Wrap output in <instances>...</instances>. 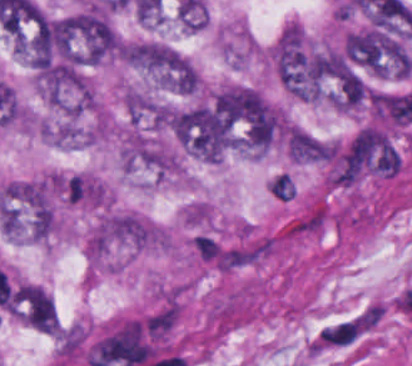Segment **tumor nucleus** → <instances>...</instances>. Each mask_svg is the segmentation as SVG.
<instances>
[{
	"instance_id": "8643909e",
	"label": "tumor nucleus",
	"mask_w": 412,
	"mask_h": 366,
	"mask_svg": "<svg viewBox=\"0 0 412 366\" xmlns=\"http://www.w3.org/2000/svg\"><path fill=\"white\" fill-rule=\"evenodd\" d=\"M125 63L136 68L164 72L171 65L172 48L159 43H126L121 48Z\"/></svg>"
},
{
	"instance_id": "2f306a5c",
	"label": "tumor nucleus",
	"mask_w": 412,
	"mask_h": 366,
	"mask_svg": "<svg viewBox=\"0 0 412 366\" xmlns=\"http://www.w3.org/2000/svg\"><path fill=\"white\" fill-rule=\"evenodd\" d=\"M151 71L163 88L190 93L196 86V74L192 66L174 50Z\"/></svg>"
}]
</instances>
